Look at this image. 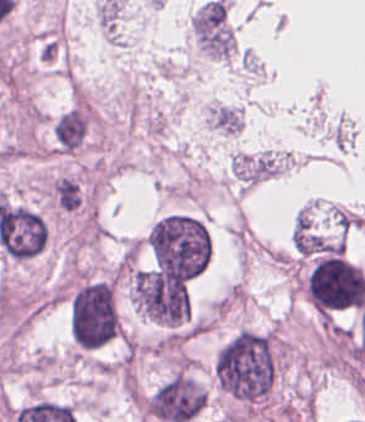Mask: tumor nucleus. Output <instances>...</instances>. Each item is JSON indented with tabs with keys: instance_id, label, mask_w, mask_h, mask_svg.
I'll use <instances>...</instances> for the list:
<instances>
[{
	"instance_id": "obj_2",
	"label": "tumor nucleus",
	"mask_w": 365,
	"mask_h": 422,
	"mask_svg": "<svg viewBox=\"0 0 365 422\" xmlns=\"http://www.w3.org/2000/svg\"><path fill=\"white\" fill-rule=\"evenodd\" d=\"M191 290L192 278L155 267H136L128 288L137 314L164 328H176L188 322Z\"/></svg>"
},
{
	"instance_id": "obj_1",
	"label": "tumor nucleus",
	"mask_w": 365,
	"mask_h": 422,
	"mask_svg": "<svg viewBox=\"0 0 365 422\" xmlns=\"http://www.w3.org/2000/svg\"><path fill=\"white\" fill-rule=\"evenodd\" d=\"M154 267L169 276L195 278L211 258L209 231L199 218L180 213L162 216L147 236Z\"/></svg>"
},
{
	"instance_id": "obj_3",
	"label": "tumor nucleus",
	"mask_w": 365,
	"mask_h": 422,
	"mask_svg": "<svg viewBox=\"0 0 365 422\" xmlns=\"http://www.w3.org/2000/svg\"><path fill=\"white\" fill-rule=\"evenodd\" d=\"M208 127L220 134L238 136L242 132L241 107L214 102L209 107Z\"/></svg>"
}]
</instances>
